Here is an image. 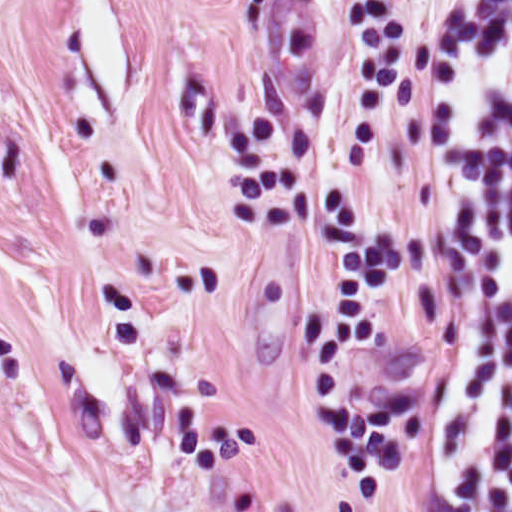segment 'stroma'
Segmentation results:
<instances>
[{"instance_id": "1", "label": "stroma", "mask_w": 512, "mask_h": 512, "mask_svg": "<svg viewBox=\"0 0 512 512\" xmlns=\"http://www.w3.org/2000/svg\"><path fill=\"white\" fill-rule=\"evenodd\" d=\"M439 0H0V512H444Z\"/></svg>"}]
</instances>
